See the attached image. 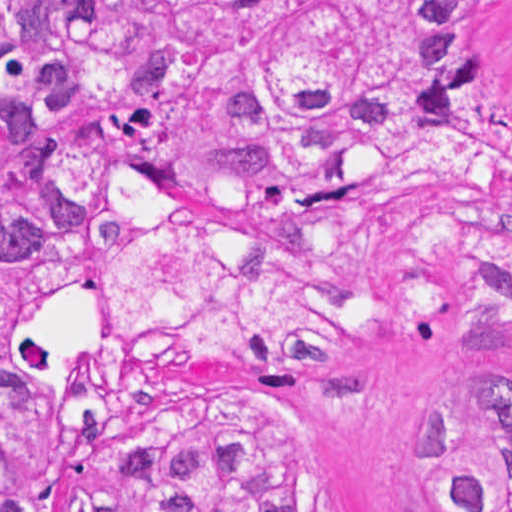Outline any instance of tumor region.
Here are the masks:
<instances>
[{"label":"tumor region","mask_w":512,"mask_h":512,"mask_svg":"<svg viewBox=\"0 0 512 512\" xmlns=\"http://www.w3.org/2000/svg\"><path fill=\"white\" fill-rule=\"evenodd\" d=\"M512 0H0V512H51L70 406L15 310L103 276L124 358L367 365L512 339ZM86 415L72 512H312L279 419ZM443 512H512V401L415 437Z\"/></svg>","instance_id":"1"}]
</instances>
